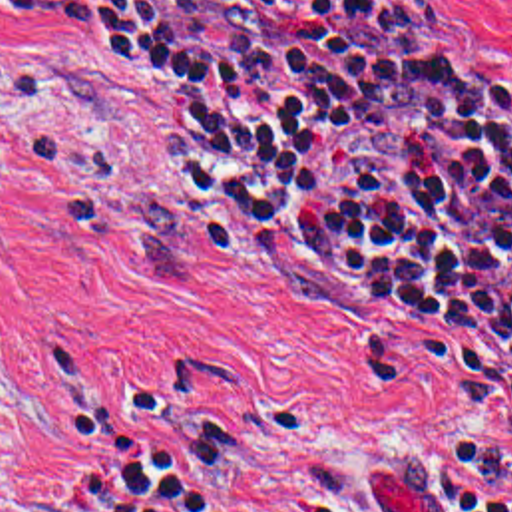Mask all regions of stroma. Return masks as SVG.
Returning <instances> with one entry per match:
<instances>
[{"mask_svg":"<svg viewBox=\"0 0 512 512\" xmlns=\"http://www.w3.org/2000/svg\"><path fill=\"white\" fill-rule=\"evenodd\" d=\"M512 119V0H424ZM495 346L276 274L177 109L0 0V512H444L434 445L512 457Z\"/></svg>","mask_w":512,"mask_h":512,"instance_id":"35a3bbf8","label":"stroma"}]
</instances>
